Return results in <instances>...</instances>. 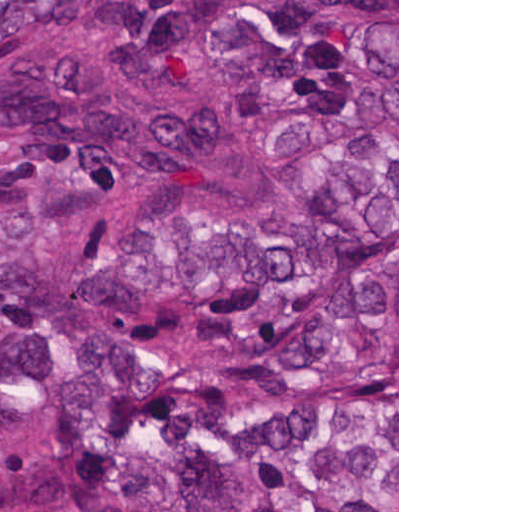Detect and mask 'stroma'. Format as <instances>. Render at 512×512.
Listing matches in <instances>:
<instances>
[{"mask_svg":"<svg viewBox=\"0 0 512 512\" xmlns=\"http://www.w3.org/2000/svg\"><path fill=\"white\" fill-rule=\"evenodd\" d=\"M0 1H397V508L399 512V0H0ZM69 50L86 60L115 86L127 106L145 120L180 114L196 102L214 109L227 123L225 141L206 146L180 175H194L203 185L183 189L210 202H278L294 209L309 225L316 244L322 278V247L312 215L264 191L240 159L243 96L240 81L206 43L198 21L183 35L165 43H69ZM333 494H254L238 501L228 512L247 509H288L300 512L333 506H354Z\"/></svg>","mask_w":512,"mask_h":512,"instance_id":"1","label":"stroma"}]
</instances>
